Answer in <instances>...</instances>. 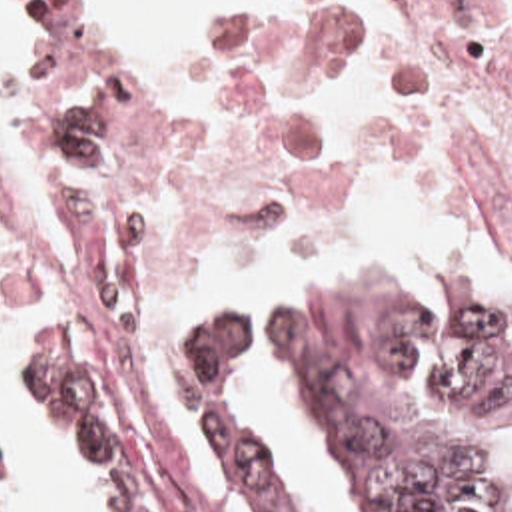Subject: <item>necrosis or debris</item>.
Listing matches in <instances>:
<instances>
[{
	"mask_svg": "<svg viewBox=\"0 0 512 512\" xmlns=\"http://www.w3.org/2000/svg\"><path fill=\"white\" fill-rule=\"evenodd\" d=\"M34 60L58 232L0 212V332L96 298L178 338L280 262L512 288V0H296L214 76H90L48 26Z\"/></svg>",
	"mask_w": 512,
	"mask_h": 512,
	"instance_id": "4bbe7bcc",
	"label": "necrosis or debris"
}]
</instances>
